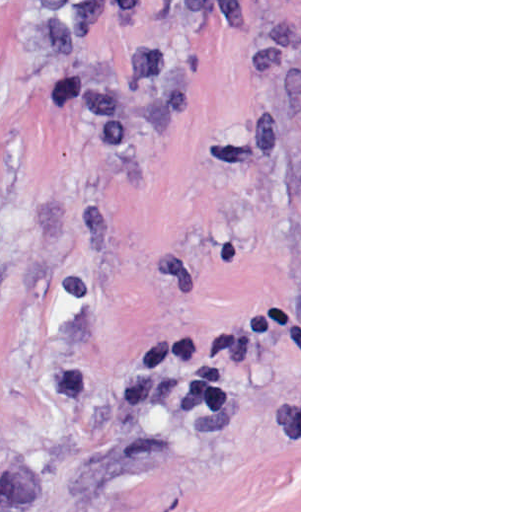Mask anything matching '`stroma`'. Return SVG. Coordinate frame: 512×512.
<instances>
[{"label": "stroma", "mask_w": 512, "mask_h": 512, "mask_svg": "<svg viewBox=\"0 0 512 512\" xmlns=\"http://www.w3.org/2000/svg\"><path fill=\"white\" fill-rule=\"evenodd\" d=\"M0 0V512H301V0Z\"/></svg>", "instance_id": "35a3bbf8"}]
</instances>
